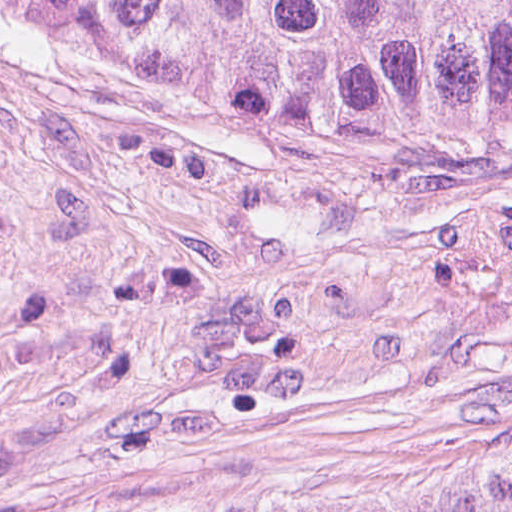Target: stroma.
<instances>
[{
	"label": "stroma",
	"mask_w": 512,
	"mask_h": 512,
	"mask_svg": "<svg viewBox=\"0 0 512 512\" xmlns=\"http://www.w3.org/2000/svg\"><path fill=\"white\" fill-rule=\"evenodd\" d=\"M509 446L512 148L254 117L0 20V512Z\"/></svg>",
	"instance_id": "obj_1"
}]
</instances>
